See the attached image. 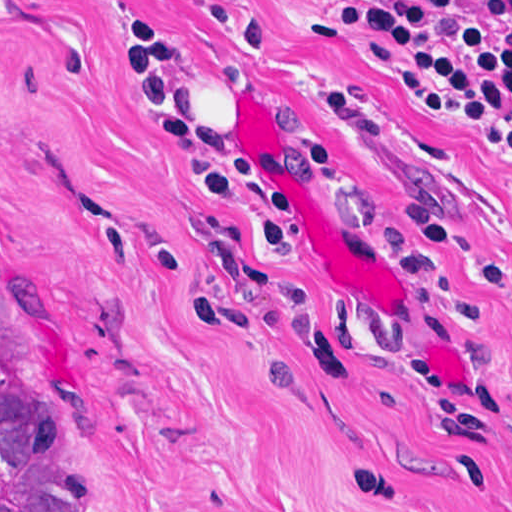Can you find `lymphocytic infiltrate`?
<instances>
[{
  "label": "lymphocytic infiltrate",
  "instance_id": "1",
  "mask_svg": "<svg viewBox=\"0 0 512 512\" xmlns=\"http://www.w3.org/2000/svg\"><path fill=\"white\" fill-rule=\"evenodd\" d=\"M171 1L254 42L262 35L243 0ZM312 1L317 12L310 27L357 40L402 98L488 134L512 154V0ZM323 14L334 23L323 20ZM119 40L143 87L156 137L191 146L204 156L208 167L196 178L199 193L215 199L245 187L264 190L271 249L292 252L302 229L300 194L253 153L224 149L202 127L177 37L162 14L135 13L122 21ZM321 87L330 114L350 142L386 138V126L355 89L335 83ZM484 141L512 169V158ZM408 195L434 215L438 249H444L446 224L440 211L431 200ZM451 311L472 325L474 308Z\"/></svg>",
  "mask_w": 512,
  "mask_h": 512
}]
</instances>
